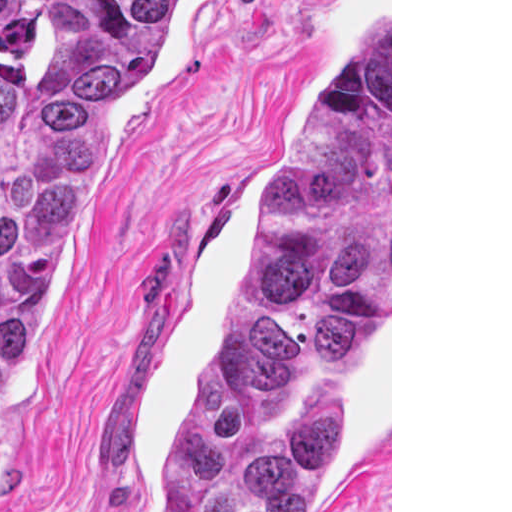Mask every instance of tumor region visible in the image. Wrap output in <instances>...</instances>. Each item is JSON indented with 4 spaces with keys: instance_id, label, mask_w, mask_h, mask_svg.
I'll list each match as a JSON object with an SVG mask.
<instances>
[{
    "instance_id": "e687c5a6",
    "label": "tumor region",
    "mask_w": 512,
    "mask_h": 512,
    "mask_svg": "<svg viewBox=\"0 0 512 512\" xmlns=\"http://www.w3.org/2000/svg\"><path fill=\"white\" fill-rule=\"evenodd\" d=\"M204 0H0V494L32 318L87 194L108 111ZM359 53L270 184L261 274L198 369L153 512H306L355 413L390 308V26Z\"/></svg>"
}]
</instances>
